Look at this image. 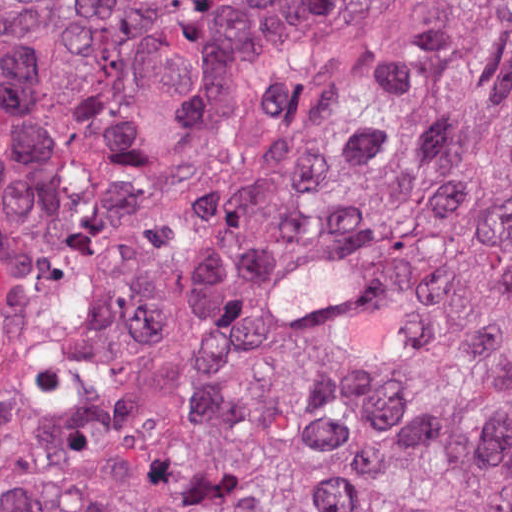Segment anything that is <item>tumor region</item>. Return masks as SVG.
<instances>
[{"mask_svg":"<svg viewBox=\"0 0 512 512\" xmlns=\"http://www.w3.org/2000/svg\"><path fill=\"white\" fill-rule=\"evenodd\" d=\"M0 512H512V0H0Z\"/></svg>","mask_w":512,"mask_h":512,"instance_id":"e687c5a6","label":"tumor region"}]
</instances>
